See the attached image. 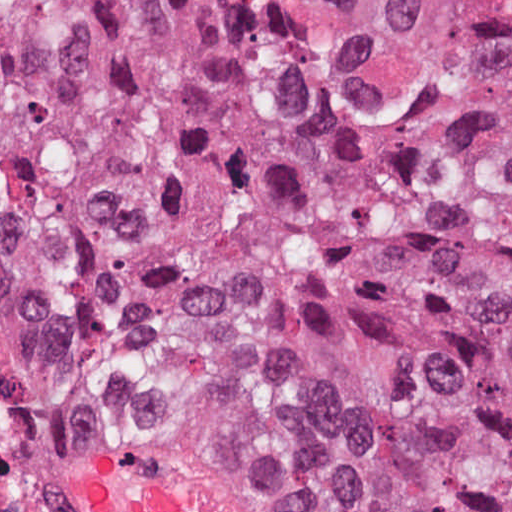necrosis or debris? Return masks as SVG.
I'll return each instance as SVG.
<instances>
[{"label": "necrosis or debris", "instance_id": "4bbe7bcc", "mask_svg": "<svg viewBox=\"0 0 512 512\" xmlns=\"http://www.w3.org/2000/svg\"><path fill=\"white\" fill-rule=\"evenodd\" d=\"M0 512H83L73 463L1 324Z\"/></svg>", "mask_w": 512, "mask_h": 512}]
</instances>
